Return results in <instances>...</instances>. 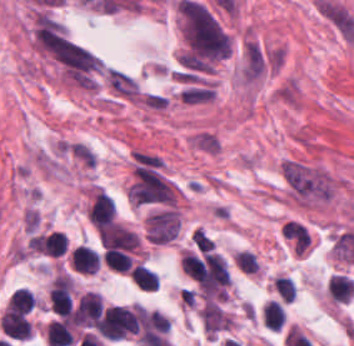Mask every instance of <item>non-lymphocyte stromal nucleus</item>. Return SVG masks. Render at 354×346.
<instances>
[{"instance_id": "non-lymphocyte-stromal-nucleus-1", "label": "non-lymphocyte stromal nucleus", "mask_w": 354, "mask_h": 346, "mask_svg": "<svg viewBox=\"0 0 354 346\" xmlns=\"http://www.w3.org/2000/svg\"><path fill=\"white\" fill-rule=\"evenodd\" d=\"M279 168L285 183L299 201L330 198L327 174L320 169L295 162H282Z\"/></svg>"}, {"instance_id": "non-lymphocyte-stromal-nucleus-2", "label": "non-lymphocyte stromal nucleus", "mask_w": 354, "mask_h": 346, "mask_svg": "<svg viewBox=\"0 0 354 346\" xmlns=\"http://www.w3.org/2000/svg\"><path fill=\"white\" fill-rule=\"evenodd\" d=\"M180 221L172 208L150 213L145 220L146 241L163 245L178 234Z\"/></svg>"}, {"instance_id": "non-lymphocyte-stromal-nucleus-3", "label": "non-lymphocyte stromal nucleus", "mask_w": 354, "mask_h": 346, "mask_svg": "<svg viewBox=\"0 0 354 346\" xmlns=\"http://www.w3.org/2000/svg\"><path fill=\"white\" fill-rule=\"evenodd\" d=\"M185 142L195 151L215 157L220 154L223 148L221 138L214 131L205 127L189 133Z\"/></svg>"}, {"instance_id": "non-lymphocyte-stromal-nucleus-4", "label": "non-lymphocyte stromal nucleus", "mask_w": 354, "mask_h": 346, "mask_svg": "<svg viewBox=\"0 0 354 346\" xmlns=\"http://www.w3.org/2000/svg\"><path fill=\"white\" fill-rule=\"evenodd\" d=\"M265 58L255 40H247L243 46L242 75L243 79L253 81L264 69Z\"/></svg>"}, {"instance_id": "non-lymphocyte-stromal-nucleus-5", "label": "non-lymphocyte stromal nucleus", "mask_w": 354, "mask_h": 346, "mask_svg": "<svg viewBox=\"0 0 354 346\" xmlns=\"http://www.w3.org/2000/svg\"><path fill=\"white\" fill-rule=\"evenodd\" d=\"M280 234L293 253H304L310 244V237L303 225L288 222L282 226Z\"/></svg>"}]
</instances>
